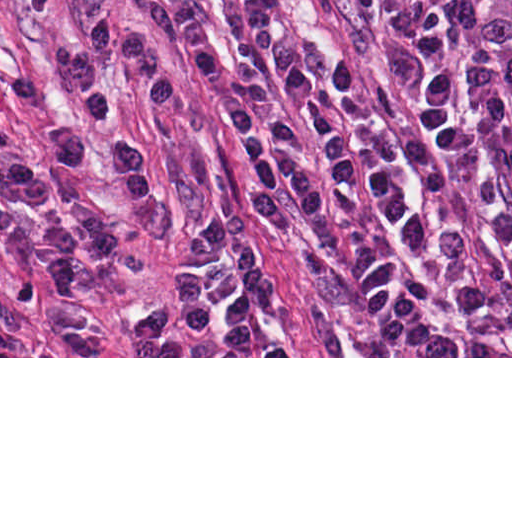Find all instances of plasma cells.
Wrapping results in <instances>:
<instances>
[{"label":"plasma cells","instance_id":"9512152a","mask_svg":"<svg viewBox=\"0 0 512 512\" xmlns=\"http://www.w3.org/2000/svg\"><path fill=\"white\" fill-rule=\"evenodd\" d=\"M435 85L397 192L340 252L334 296L363 356H512V0H398ZM282 283L225 213L188 239L175 301L135 320L148 356L214 327L246 347Z\"/></svg>","mask_w":512,"mask_h":512}]
</instances>
